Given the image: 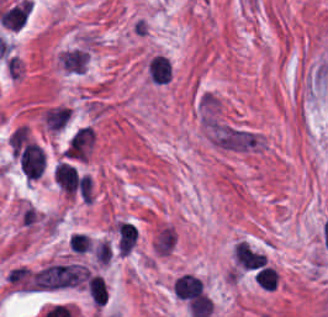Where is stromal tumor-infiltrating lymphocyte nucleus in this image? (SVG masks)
Segmentation results:
<instances>
[{
  "instance_id": "stromal-tumor-infiltrating-lymphocyte-nucleus-1",
  "label": "stromal tumor-infiltrating lymphocyte nucleus",
  "mask_w": 328,
  "mask_h": 317,
  "mask_svg": "<svg viewBox=\"0 0 328 317\" xmlns=\"http://www.w3.org/2000/svg\"><path fill=\"white\" fill-rule=\"evenodd\" d=\"M95 134L88 125L76 127L69 135L62 155L66 159L84 160L94 145Z\"/></svg>"
},
{
  "instance_id": "stromal-tumor-infiltrating-lymphocyte-nucleus-3",
  "label": "stromal tumor-infiltrating lymphocyte nucleus",
  "mask_w": 328,
  "mask_h": 317,
  "mask_svg": "<svg viewBox=\"0 0 328 317\" xmlns=\"http://www.w3.org/2000/svg\"><path fill=\"white\" fill-rule=\"evenodd\" d=\"M173 292L175 296L189 300L200 296L199 276L189 273L177 275L173 280Z\"/></svg>"
},
{
  "instance_id": "stromal-tumor-infiltrating-lymphocyte-nucleus-2",
  "label": "stromal tumor-infiltrating lymphocyte nucleus",
  "mask_w": 328,
  "mask_h": 317,
  "mask_svg": "<svg viewBox=\"0 0 328 317\" xmlns=\"http://www.w3.org/2000/svg\"><path fill=\"white\" fill-rule=\"evenodd\" d=\"M54 177L63 192L71 197L81 181L76 168L66 160H59L55 165Z\"/></svg>"
}]
</instances>
